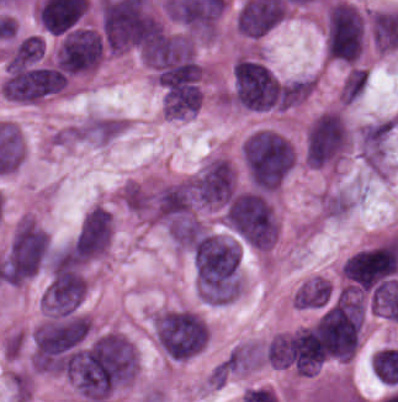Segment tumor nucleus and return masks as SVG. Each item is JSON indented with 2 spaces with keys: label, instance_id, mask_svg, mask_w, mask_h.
<instances>
[{
  "label": "tumor nucleus",
  "instance_id": "2f306a5c",
  "mask_svg": "<svg viewBox=\"0 0 398 402\" xmlns=\"http://www.w3.org/2000/svg\"><path fill=\"white\" fill-rule=\"evenodd\" d=\"M241 154L253 188H281L296 165L298 152L283 132L258 127L242 143Z\"/></svg>",
  "mask_w": 398,
  "mask_h": 402
},
{
  "label": "tumor nucleus",
  "instance_id": "8643909e",
  "mask_svg": "<svg viewBox=\"0 0 398 402\" xmlns=\"http://www.w3.org/2000/svg\"><path fill=\"white\" fill-rule=\"evenodd\" d=\"M150 325L160 352L181 360L203 350L210 333L201 313L189 306H163L153 311Z\"/></svg>",
  "mask_w": 398,
  "mask_h": 402
},
{
  "label": "tumor nucleus",
  "instance_id": "5ab6c2c4",
  "mask_svg": "<svg viewBox=\"0 0 398 402\" xmlns=\"http://www.w3.org/2000/svg\"><path fill=\"white\" fill-rule=\"evenodd\" d=\"M50 238L33 216H20L12 226L0 262V281L22 286L42 268Z\"/></svg>",
  "mask_w": 398,
  "mask_h": 402
},
{
  "label": "tumor nucleus",
  "instance_id": "2cbd58db",
  "mask_svg": "<svg viewBox=\"0 0 398 402\" xmlns=\"http://www.w3.org/2000/svg\"><path fill=\"white\" fill-rule=\"evenodd\" d=\"M367 40V14L346 0L325 5L322 20L324 57L345 63H358Z\"/></svg>",
  "mask_w": 398,
  "mask_h": 402
},
{
  "label": "tumor nucleus",
  "instance_id": "3d1891a8",
  "mask_svg": "<svg viewBox=\"0 0 398 402\" xmlns=\"http://www.w3.org/2000/svg\"><path fill=\"white\" fill-rule=\"evenodd\" d=\"M351 145V125L339 108L318 111L305 128L303 162L315 168H336Z\"/></svg>",
  "mask_w": 398,
  "mask_h": 402
},
{
  "label": "tumor nucleus",
  "instance_id": "2083b535",
  "mask_svg": "<svg viewBox=\"0 0 398 402\" xmlns=\"http://www.w3.org/2000/svg\"><path fill=\"white\" fill-rule=\"evenodd\" d=\"M115 220L109 209L94 204L85 215L68 247L86 262L105 258L114 235Z\"/></svg>",
  "mask_w": 398,
  "mask_h": 402
},
{
  "label": "tumor nucleus",
  "instance_id": "8087334f",
  "mask_svg": "<svg viewBox=\"0 0 398 402\" xmlns=\"http://www.w3.org/2000/svg\"><path fill=\"white\" fill-rule=\"evenodd\" d=\"M262 366V342L254 338L241 341L224 357L226 375H246Z\"/></svg>",
  "mask_w": 398,
  "mask_h": 402
},
{
  "label": "tumor nucleus",
  "instance_id": "c2bd9aea",
  "mask_svg": "<svg viewBox=\"0 0 398 402\" xmlns=\"http://www.w3.org/2000/svg\"><path fill=\"white\" fill-rule=\"evenodd\" d=\"M118 202L141 222H149L153 198L147 183L126 179L118 189Z\"/></svg>",
  "mask_w": 398,
  "mask_h": 402
},
{
  "label": "tumor nucleus",
  "instance_id": "feef74b5",
  "mask_svg": "<svg viewBox=\"0 0 398 402\" xmlns=\"http://www.w3.org/2000/svg\"><path fill=\"white\" fill-rule=\"evenodd\" d=\"M356 202L357 195L353 191L325 189L316 200V213L320 220H339L349 214Z\"/></svg>",
  "mask_w": 398,
  "mask_h": 402
},
{
  "label": "tumor nucleus",
  "instance_id": "3e47fb67",
  "mask_svg": "<svg viewBox=\"0 0 398 402\" xmlns=\"http://www.w3.org/2000/svg\"><path fill=\"white\" fill-rule=\"evenodd\" d=\"M332 292L331 282L321 274L306 278L294 291V307H320Z\"/></svg>",
  "mask_w": 398,
  "mask_h": 402
},
{
  "label": "tumor nucleus",
  "instance_id": "f7901128",
  "mask_svg": "<svg viewBox=\"0 0 398 402\" xmlns=\"http://www.w3.org/2000/svg\"><path fill=\"white\" fill-rule=\"evenodd\" d=\"M367 69L348 68L338 88V101L351 105L366 88Z\"/></svg>",
  "mask_w": 398,
  "mask_h": 402
}]
</instances>
